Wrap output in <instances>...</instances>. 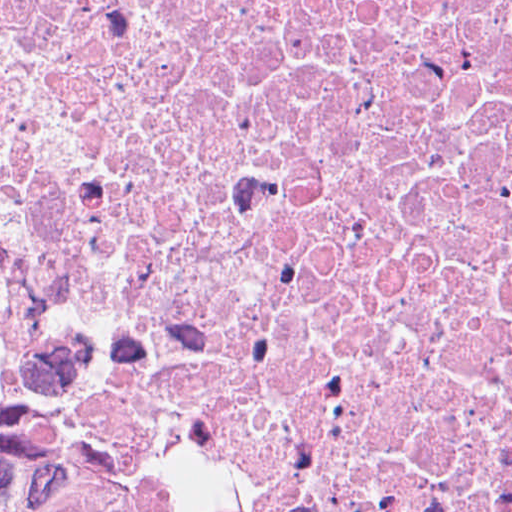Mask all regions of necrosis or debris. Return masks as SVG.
<instances>
[{"instance_id":"obj_1","label":"necrosis or debris","mask_w":512,"mask_h":512,"mask_svg":"<svg viewBox=\"0 0 512 512\" xmlns=\"http://www.w3.org/2000/svg\"><path fill=\"white\" fill-rule=\"evenodd\" d=\"M0 512H512V0H0Z\"/></svg>"}]
</instances>
